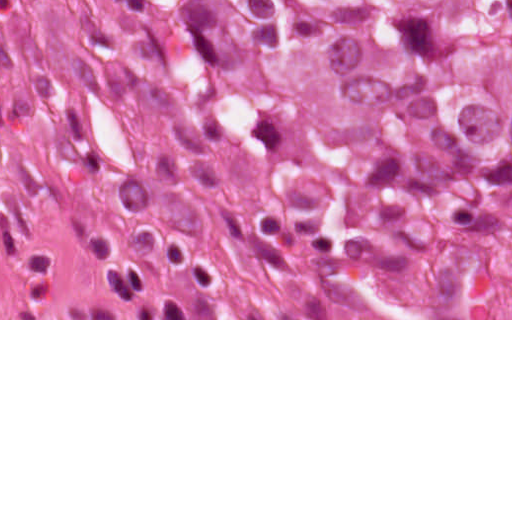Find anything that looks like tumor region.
<instances>
[{
  "label": "tumor region",
  "instance_id": "e687c5a6",
  "mask_svg": "<svg viewBox=\"0 0 512 512\" xmlns=\"http://www.w3.org/2000/svg\"><path fill=\"white\" fill-rule=\"evenodd\" d=\"M129 93L199 319H512V0H41Z\"/></svg>",
  "mask_w": 512,
  "mask_h": 512
}]
</instances>
